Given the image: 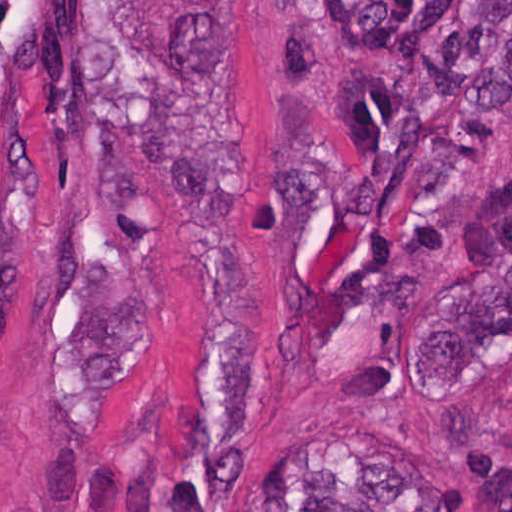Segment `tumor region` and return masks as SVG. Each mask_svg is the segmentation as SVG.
Segmentation results:
<instances>
[{
  "instance_id": "1",
  "label": "tumor region",
  "mask_w": 512,
  "mask_h": 512,
  "mask_svg": "<svg viewBox=\"0 0 512 512\" xmlns=\"http://www.w3.org/2000/svg\"><path fill=\"white\" fill-rule=\"evenodd\" d=\"M46 1H0V185L18 74ZM149 186L194 252L192 393L184 451L145 512H227L225 470L251 432L254 372L240 222L198 1H103ZM294 13V132L302 222L324 200L370 225L362 275L430 167L512 93V1H285ZM449 349L466 365L512 349V211L482 244L478 292ZM236 512H465L430 470L279 480Z\"/></svg>"
}]
</instances>
